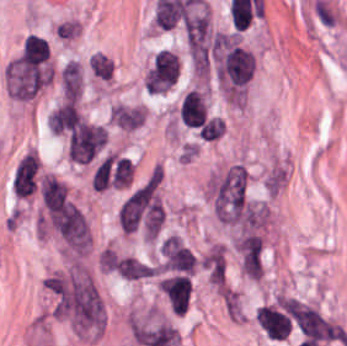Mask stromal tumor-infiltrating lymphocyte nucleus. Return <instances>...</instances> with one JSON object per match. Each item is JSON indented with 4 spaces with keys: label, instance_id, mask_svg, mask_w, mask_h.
I'll return each instance as SVG.
<instances>
[{
    "label": "stromal tumor-infiltrating lymphocyte nucleus",
    "instance_id": "abfb95fc",
    "mask_svg": "<svg viewBox=\"0 0 347 346\" xmlns=\"http://www.w3.org/2000/svg\"><path fill=\"white\" fill-rule=\"evenodd\" d=\"M84 120L75 103L70 99L57 107L48 119V124L59 134L73 130Z\"/></svg>",
    "mask_w": 347,
    "mask_h": 346
},
{
    "label": "stromal tumor-infiltrating lymphocyte nucleus",
    "instance_id": "f3e2335f",
    "mask_svg": "<svg viewBox=\"0 0 347 346\" xmlns=\"http://www.w3.org/2000/svg\"><path fill=\"white\" fill-rule=\"evenodd\" d=\"M92 74L99 78L111 80L113 78L114 62L106 55L95 53L88 59Z\"/></svg>",
    "mask_w": 347,
    "mask_h": 346
},
{
    "label": "stromal tumor-infiltrating lymphocyte nucleus",
    "instance_id": "3290ff9b",
    "mask_svg": "<svg viewBox=\"0 0 347 346\" xmlns=\"http://www.w3.org/2000/svg\"><path fill=\"white\" fill-rule=\"evenodd\" d=\"M37 177V159L34 152H27L17 163L13 176L15 196L25 197L34 191Z\"/></svg>",
    "mask_w": 347,
    "mask_h": 346
},
{
    "label": "stromal tumor-infiltrating lymphocyte nucleus",
    "instance_id": "52c7bb5b",
    "mask_svg": "<svg viewBox=\"0 0 347 346\" xmlns=\"http://www.w3.org/2000/svg\"><path fill=\"white\" fill-rule=\"evenodd\" d=\"M210 115L205 92L199 88H192L184 96L181 104V122L195 131Z\"/></svg>",
    "mask_w": 347,
    "mask_h": 346
},
{
    "label": "stromal tumor-infiltrating lymphocyte nucleus",
    "instance_id": "bc302bb0",
    "mask_svg": "<svg viewBox=\"0 0 347 346\" xmlns=\"http://www.w3.org/2000/svg\"><path fill=\"white\" fill-rule=\"evenodd\" d=\"M256 319L259 328L273 341H283L291 333V314L281 301L262 305L256 311Z\"/></svg>",
    "mask_w": 347,
    "mask_h": 346
},
{
    "label": "stromal tumor-infiltrating lymphocyte nucleus",
    "instance_id": "9ea309e8",
    "mask_svg": "<svg viewBox=\"0 0 347 346\" xmlns=\"http://www.w3.org/2000/svg\"><path fill=\"white\" fill-rule=\"evenodd\" d=\"M197 132L204 141H214L223 136L225 121L215 115H208Z\"/></svg>",
    "mask_w": 347,
    "mask_h": 346
}]
</instances>
